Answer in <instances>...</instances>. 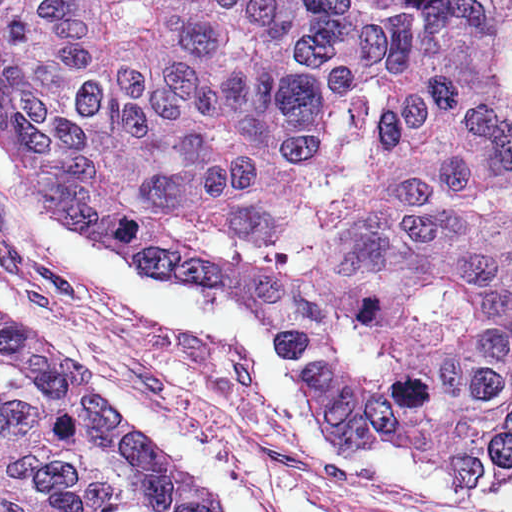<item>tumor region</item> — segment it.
Listing matches in <instances>:
<instances>
[{
    "label": "tumor region",
    "instance_id": "obj_1",
    "mask_svg": "<svg viewBox=\"0 0 512 512\" xmlns=\"http://www.w3.org/2000/svg\"><path fill=\"white\" fill-rule=\"evenodd\" d=\"M0 145L142 270L283 315L333 452L512 481V0H0ZM0 512H206L0 323Z\"/></svg>",
    "mask_w": 512,
    "mask_h": 512
}]
</instances>
